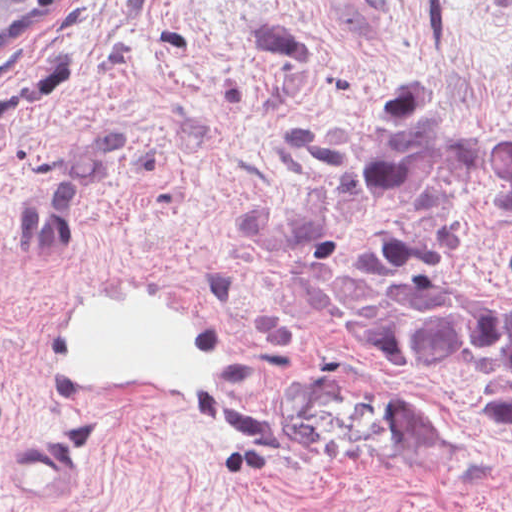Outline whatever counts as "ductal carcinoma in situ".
<instances>
[{"instance_id": "0f090b9a", "label": "ductal carcinoma in situ", "mask_w": 512, "mask_h": 512, "mask_svg": "<svg viewBox=\"0 0 512 512\" xmlns=\"http://www.w3.org/2000/svg\"><path fill=\"white\" fill-rule=\"evenodd\" d=\"M82 0H0V67L40 41Z\"/></svg>"}]
</instances>
